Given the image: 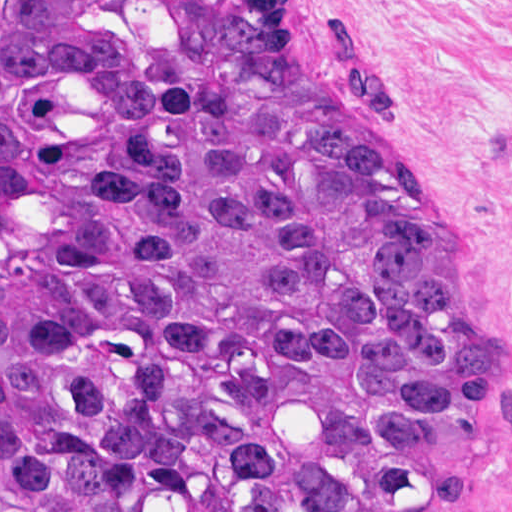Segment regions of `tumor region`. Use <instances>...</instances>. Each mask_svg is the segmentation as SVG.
Segmentation results:
<instances>
[{"instance_id": "tumor-region-1", "label": "tumor region", "mask_w": 512, "mask_h": 512, "mask_svg": "<svg viewBox=\"0 0 512 512\" xmlns=\"http://www.w3.org/2000/svg\"><path fill=\"white\" fill-rule=\"evenodd\" d=\"M510 437L479 283L280 0H0V512H449Z\"/></svg>"}]
</instances>
